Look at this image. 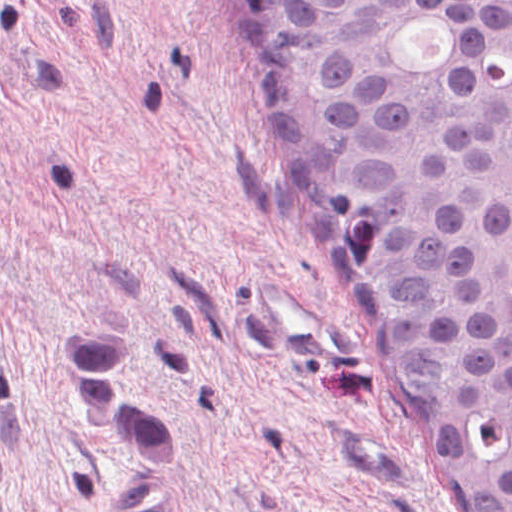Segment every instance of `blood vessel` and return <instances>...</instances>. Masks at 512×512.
I'll list each match as a JSON object with an SVG mask.
<instances>
[{"mask_svg":"<svg viewBox=\"0 0 512 512\" xmlns=\"http://www.w3.org/2000/svg\"><path fill=\"white\" fill-rule=\"evenodd\" d=\"M241 283L249 310L295 361L311 369L348 371L351 326L345 317L318 311L265 277Z\"/></svg>","mask_w":512,"mask_h":512,"instance_id":"blood-vessel-1","label":"blood vessel"}]
</instances>
